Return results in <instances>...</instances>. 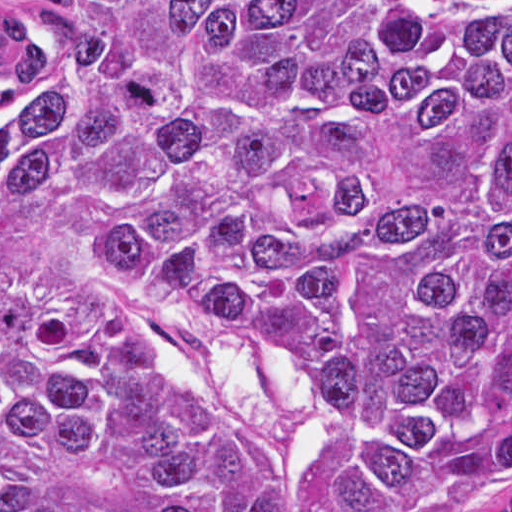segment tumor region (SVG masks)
<instances>
[{
	"mask_svg": "<svg viewBox=\"0 0 512 512\" xmlns=\"http://www.w3.org/2000/svg\"><path fill=\"white\" fill-rule=\"evenodd\" d=\"M0 280L238 331L368 435L315 512H512V0H0ZM0 512H293L129 313L0 289Z\"/></svg>",
	"mask_w": 512,
	"mask_h": 512,
	"instance_id": "tumor-region-1",
	"label": "tumor region"
}]
</instances>
